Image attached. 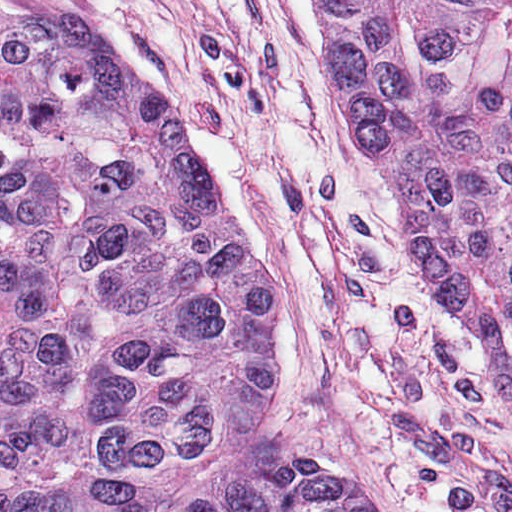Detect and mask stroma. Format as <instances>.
I'll return each instance as SVG.
<instances>
[{
	"mask_svg": "<svg viewBox=\"0 0 512 512\" xmlns=\"http://www.w3.org/2000/svg\"><path fill=\"white\" fill-rule=\"evenodd\" d=\"M0 7L63 12L153 87L278 299L270 417L160 512H201L230 481L300 455L390 512H512V373L424 304L391 175L319 64L315 0Z\"/></svg>",
	"mask_w": 512,
	"mask_h": 512,
	"instance_id": "1",
	"label": "stroma"
}]
</instances>
